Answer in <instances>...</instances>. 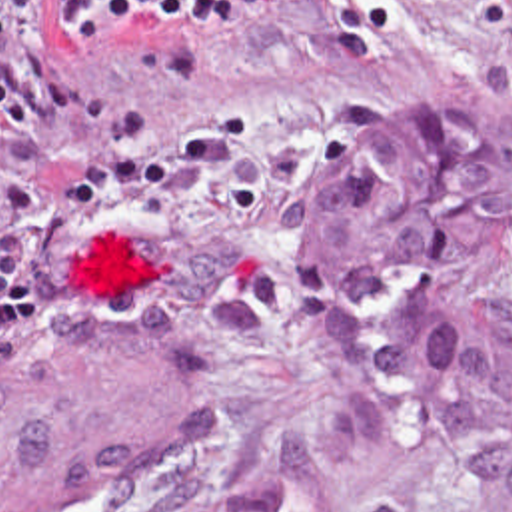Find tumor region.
Returning <instances> with one entry per match:
<instances>
[{"mask_svg": "<svg viewBox=\"0 0 512 512\" xmlns=\"http://www.w3.org/2000/svg\"><path fill=\"white\" fill-rule=\"evenodd\" d=\"M512 120L453 108L359 146L299 216L297 294L347 370L243 491L173 512H371L411 473L481 471L512 512ZM149 324L135 308L121 324ZM219 384L213 378V438Z\"/></svg>", "mask_w": 512, "mask_h": 512, "instance_id": "1", "label": "tumor region"}]
</instances>
